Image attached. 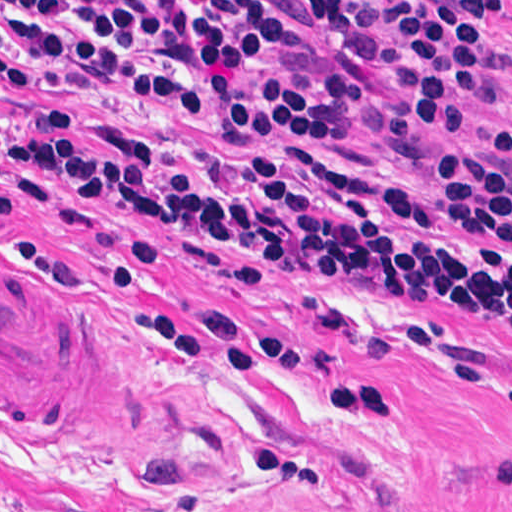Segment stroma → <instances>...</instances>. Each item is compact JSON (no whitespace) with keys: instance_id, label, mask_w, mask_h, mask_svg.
Returning a JSON list of instances; mask_svg holds the SVG:
<instances>
[{"instance_id":"1","label":"stroma","mask_w":512,"mask_h":512,"mask_svg":"<svg viewBox=\"0 0 512 512\" xmlns=\"http://www.w3.org/2000/svg\"><path fill=\"white\" fill-rule=\"evenodd\" d=\"M150 3L160 0H44ZM282 49L256 75L308 82L331 68L365 80L353 136L323 158L401 182L434 177L474 148L512 97V0L493 38L509 47L469 125L391 141L401 64L375 0H347L355 31L322 38L289 0H260ZM48 117L161 148H214L198 110L103 81L16 89L0 82V258L108 328L153 390L152 424L122 434H44L0 425V512H512V328L420 302L360 277L267 265L239 277L190 257L158 228L134 250V216L48 183L29 200L7 153Z\"/></svg>"}]
</instances>
